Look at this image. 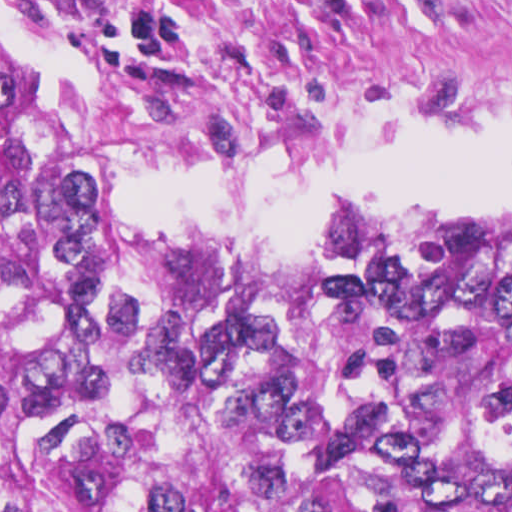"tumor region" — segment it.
Masks as SVG:
<instances>
[{
	"label": "tumor region",
	"mask_w": 512,
	"mask_h": 512,
	"mask_svg": "<svg viewBox=\"0 0 512 512\" xmlns=\"http://www.w3.org/2000/svg\"><path fill=\"white\" fill-rule=\"evenodd\" d=\"M0 58V512H512V229L232 253L48 169Z\"/></svg>",
	"instance_id": "tumor-region-1"
}]
</instances>
